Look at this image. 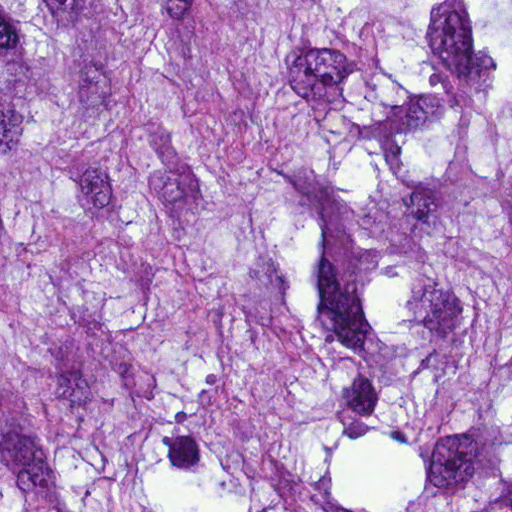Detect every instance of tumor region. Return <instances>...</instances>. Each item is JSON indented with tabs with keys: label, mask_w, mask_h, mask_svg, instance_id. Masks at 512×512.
Listing matches in <instances>:
<instances>
[{
	"label": "tumor region",
	"mask_w": 512,
	"mask_h": 512,
	"mask_svg": "<svg viewBox=\"0 0 512 512\" xmlns=\"http://www.w3.org/2000/svg\"><path fill=\"white\" fill-rule=\"evenodd\" d=\"M0 512H512V0H0Z\"/></svg>",
	"instance_id": "1"
}]
</instances>
